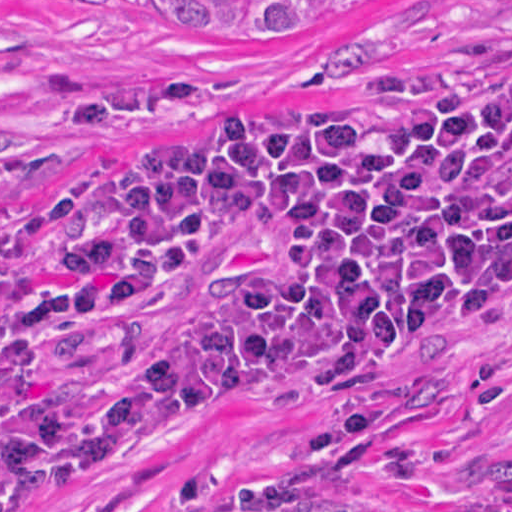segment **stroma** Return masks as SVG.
I'll return each instance as SVG.
<instances>
[{
	"label": "stroma",
	"instance_id": "obj_1",
	"mask_svg": "<svg viewBox=\"0 0 512 512\" xmlns=\"http://www.w3.org/2000/svg\"><path fill=\"white\" fill-rule=\"evenodd\" d=\"M512 66V0H417L260 38L182 35L162 0H0V194L37 229L0 276L58 274L134 141L168 111L274 120L471 84ZM512 181V134L492 158ZM281 240L216 256L141 306L0 357V453L107 361L279 272ZM512 496V316L478 347L349 387H271L197 440L42 512H488Z\"/></svg>",
	"mask_w": 512,
	"mask_h": 512
}]
</instances>
